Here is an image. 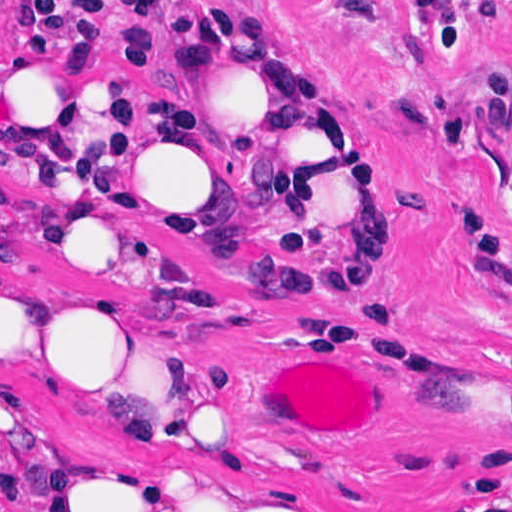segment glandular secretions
<instances>
[{
	"instance_id": "obj_1",
	"label": "glandular secretions",
	"mask_w": 512,
	"mask_h": 512,
	"mask_svg": "<svg viewBox=\"0 0 512 512\" xmlns=\"http://www.w3.org/2000/svg\"><path fill=\"white\" fill-rule=\"evenodd\" d=\"M334 357L339 358V356H334ZM285 363H329V362L327 360H325L324 358L319 357V358H314V359H310V360H293V361L282 362V363L275 364L274 367H276L277 365H280V364H285ZM350 367H352V366H350ZM354 370L357 371L356 369H354ZM368 392H369V390H368ZM369 394L372 397L370 392H369ZM372 399H373V397H372ZM373 401H374V399H373ZM374 404H375V418H374V421H373L372 425L370 426L369 430L367 432L361 434L359 437H357V438H355V439H353L351 441H348V442H309V443L319 444V445H334V444H338V443H355V442H361V441L367 440L368 438L373 436V434H374V432H375V430L377 428V405H376L375 401H374ZM242 410L247 413L246 408H245V398H244V403H243ZM265 427L269 428V429H273L271 427L269 421H268V418H267V422H266V426ZM316 449L327 450V451H390V450H333V449H325V448H316Z\"/></svg>"
}]
</instances>
